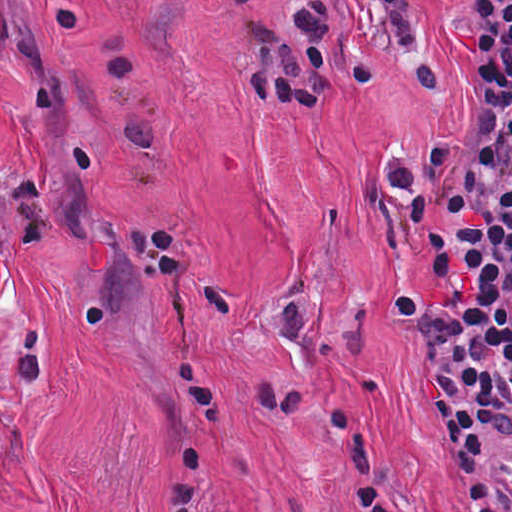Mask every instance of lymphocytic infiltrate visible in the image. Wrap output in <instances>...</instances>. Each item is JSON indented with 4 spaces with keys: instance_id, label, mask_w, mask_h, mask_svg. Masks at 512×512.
Wrapping results in <instances>:
<instances>
[{
    "instance_id": "obj_1",
    "label": "lymphocytic infiltrate",
    "mask_w": 512,
    "mask_h": 512,
    "mask_svg": "<svg viewBox=\"0 0 512 512\" xmlns=\"http://www.w3.org/2000/svg\"><path fill=\"white\" fill-rule=\"evenodd\" d=\"M346 0H286L281 15L240 12L246 65L235 75L259 107L315 116L343 71L372 77L340 43ZM376 35L411 55L422 89L428 61L415 0H356ZM477 45L462 144L385 183L423 236L439 287L405 286L391 326L430 363V405L466 512H512V0H470Z\"/></svg>"
}]
</instances>
